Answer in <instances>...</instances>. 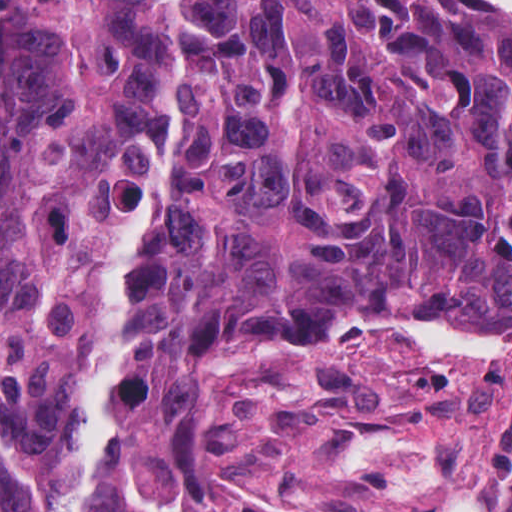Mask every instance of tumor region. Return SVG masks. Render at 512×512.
<instances>
[{
    "label": "tumor region",
    "instance_id": "1",
    "mask_svg": "<svg viewBox=\"0 0 512 512\" xmlns=\"http://www.w3.org/2000/svg\"><path fill=\"white\" fill-rule=\"evenodd\" d=\"M482 334L512 345L511 18L0 0V512H282L201 457L208 382Z\"/></svg>",
    "mask_w": 512,
    "mask_h": 512
}]
</instances>
